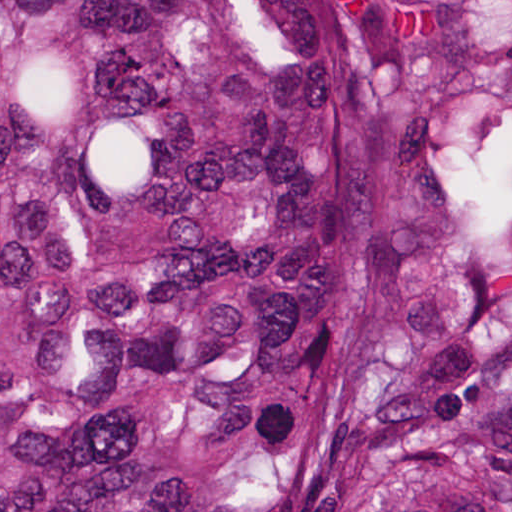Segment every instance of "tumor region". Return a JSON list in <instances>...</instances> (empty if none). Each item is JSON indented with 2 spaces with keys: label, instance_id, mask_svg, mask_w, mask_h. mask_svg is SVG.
<instances>
[{
  "label": "tumor region",
  "instance_id": "1",
  "mask_svg": "<svg viewBox=\"0 0 512 512\" xmlns=\"http://www.w3.org/2000/svg\"><path fill=\"white\" fill-rule=\"evenodd\" d=\"M0 512H512V0H0Z\"/></svg>",
  "mask_w": 512,
  "mask_h": 512
}]
</instances>
